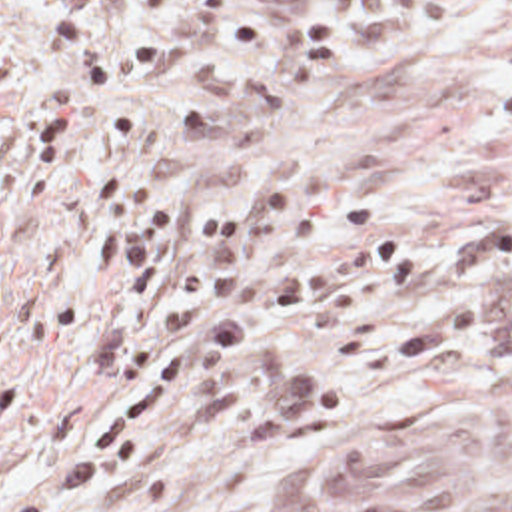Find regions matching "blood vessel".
<instances>
[{"instance_id":"obj_1","label":"blood vessel","mask_w":512,"mask_h":512,"mask_svg":"<svg viewBox=\"0 0 512 512\" xmlns=\"http://www.w3.org/2000/svg\"><path fill=\"white\" fill-rule=\"evenodd\" d=\"M404 418L321 454L289 498L303 512H428L470 494L480 432L450 414Z\"/></svg>"}]
</instances>
